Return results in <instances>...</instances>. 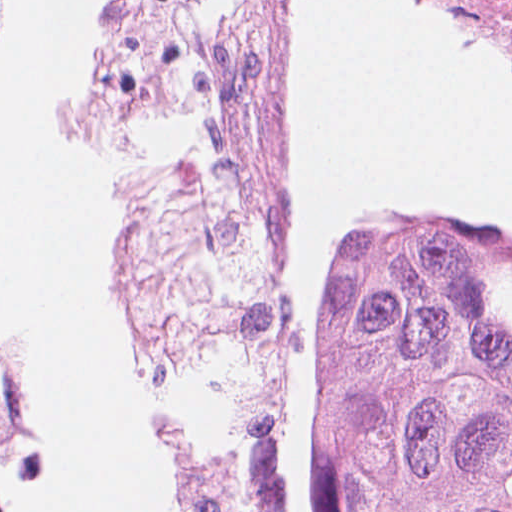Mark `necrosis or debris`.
Returning <instances> with one entry per match:
<instances>
[{"label": "necrosis or debris", "instance_id": "necrosis-or-debris-1", "mask_svg": "<svg viewBox=\"0 0 512 512\" xmlns=\"http://www.w3.org/2000/svg\"><path fill=\"white\" fill-rule=\"evenodd\" d=\"M304 0H172L158 163L114 195L116 335L208 353L211 425L163 433L157 512H280L267 470L279 314L265 275Z\"/></svg>", "mask_w": 512, "mask_h": 512}]
</instances>
